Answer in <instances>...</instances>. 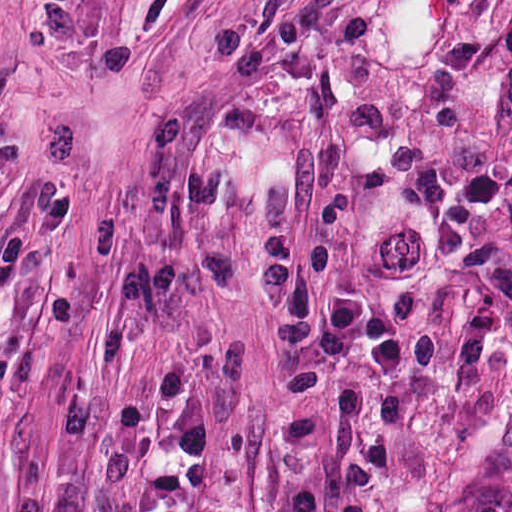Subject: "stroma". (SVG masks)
I'll return each mask as SVG.
<instances>
[{"instance_id":"35a3bbf8","label":"stroma","mask_w":512,"mask_h":512,"mask_svg":"<svg viewBox=\"0 0 512 512\" xmlns=\"http://www.w3.org/2000/svg\"><path fill=\"white\" fill-rule=\"evenodd\" d=\"M60 190L0 309V512H144L116 423L171 355L213 460L152 418L146 468L200 512L326 494L365 386L407 407L370 512L512 498V0H0V238ZM283 233L291 269L322 243L329 285L389 310L406 376L358 349L320 403L285 399L254 313Z\"/></svg>"}]
</instances>
